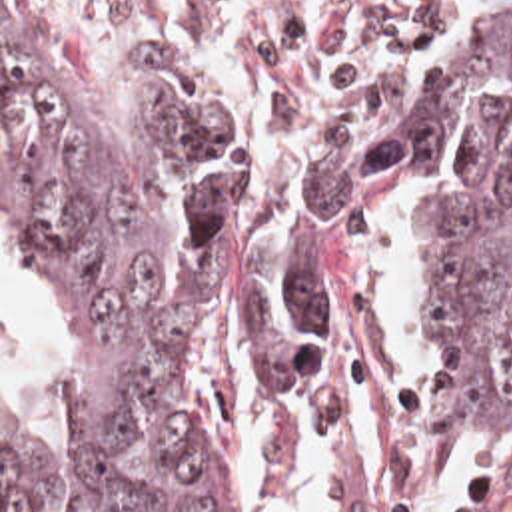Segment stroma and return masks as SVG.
Listing matches in <instances>:
<instances>
[{"instance_id": "35a3bbf8", "label": "stroma", "mask_w": 512, "mask_h": 512, "mask_svg": "<svg viewBox=\"0 0 512 512\" xmlns=\"http://www.w3.org/2000/svg\"><path fill=\"white\" fill-rule=\"evenodd\" d=\"M78 92L94 104L170 88L230 118L240 136L236 194L214 234L273 196L283 160L355 124L381 142L431 84L451 46L512 24V0H38ZM429 178L387 164L379 212L331 302L307 410H269L271 468L287 512H303L295 466L309 428L345 408V366H375L387 424L409 472L429 480L479 452L463 512H512V430L477 450L445 400L413 310V240ZM345 512H373L345 452Z\"/></svg>"}]
</instances>
